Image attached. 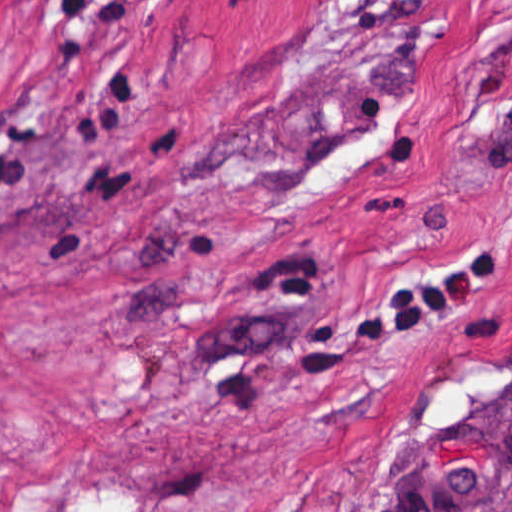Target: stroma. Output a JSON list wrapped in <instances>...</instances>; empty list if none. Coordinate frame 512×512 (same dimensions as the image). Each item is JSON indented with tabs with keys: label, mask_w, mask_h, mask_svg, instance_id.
<instances>
[{
	"label": "stroma",
	"mask_w": 512,
	"mask_h": 512,
	"mask_svg": "<svg viewBox=\"0 0 512 512\" xmlns=\"http://www.w3.org/2000/svg\"><path fill=\"white\" fill-rule=\"evenodd\" d=\"M511 201L512 0H0V512H512Z\"/></svg>",
	"instance_id": "35a3bbf8"
}]
</instances>
